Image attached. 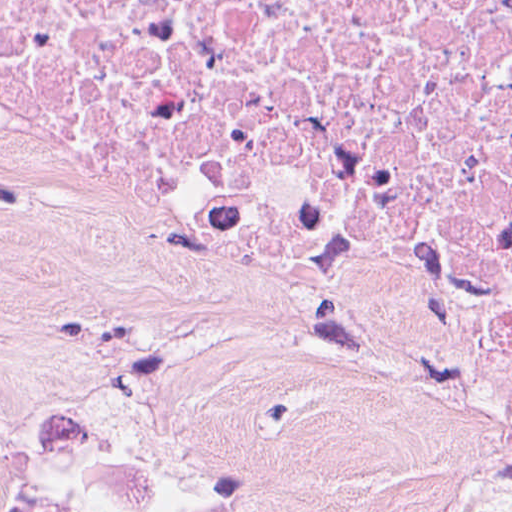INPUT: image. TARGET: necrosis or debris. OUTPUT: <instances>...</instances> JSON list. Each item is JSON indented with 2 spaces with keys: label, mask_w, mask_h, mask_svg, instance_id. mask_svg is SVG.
<instances>
[{
  "label": "necrosis or debris",
  "mask_w": 512,
  "mask_h": 512,
  "mask_svg": "<svg viewBox=\"0 0 512 512\" xmlns=\"http://www.w3.org/2000/svg\"><path fill=\"white\" fill-rule=\"evenodd\" d=\"M0 164L109 264L512 464V0H0Z\"/></svg>",
  "instance_id": "obj_1"
}]
</instances>
